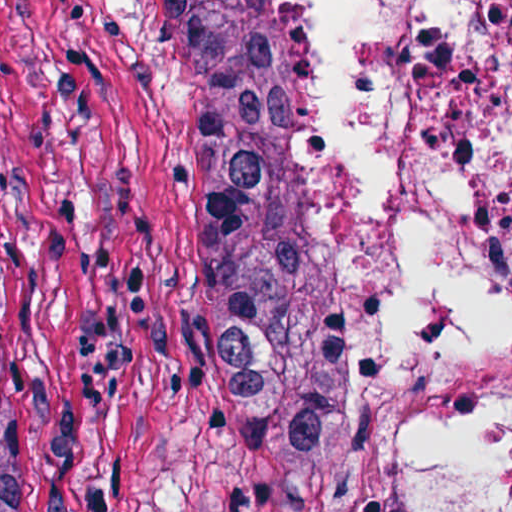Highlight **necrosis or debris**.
<instances>
[{
  "instance_id": "1",
  "label": "necrosis or debris",
  "mask_w": 512,
  "mask_h": 512,
  "mask_svg": "<svg viewBox=\"0 0 512 512\" xmlns=\"http://www.w3.org/2000/svg\"><path fill=\"white\" fill-rule=\"evenodd\" d=\"M397 512H512V0H266Z\"/></svg>"
}]
</instances>
